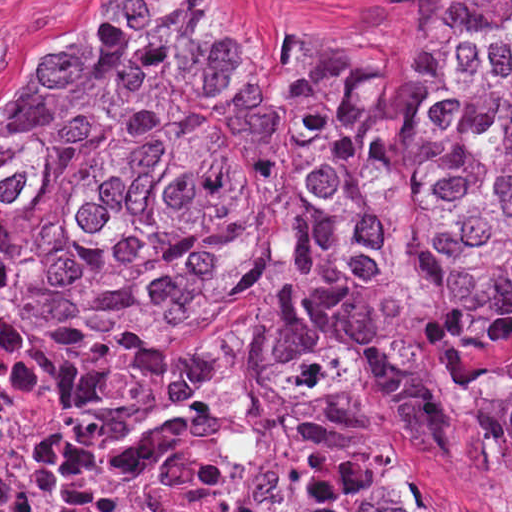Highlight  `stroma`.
<instances>
[{"label":"stroma","instance_id":"stroma-1","mask_svg":"<svg viewBox=\"0 0 512 512\" xmlns=\"http://www.w3.org/2000/svg\"><path fill=\"white\" fill-rule=\"evenodd\" d=\"M141 0H0V118L20 77L44 52ZM252 30L281 35H374L444 24L445 0H240ZM512 362V340L495 353ZM416 512H512V498L469 474L445 444L429 443L416 476Z\"/></svg>","mask_w":512,"mask_h":512}]
</instances>
